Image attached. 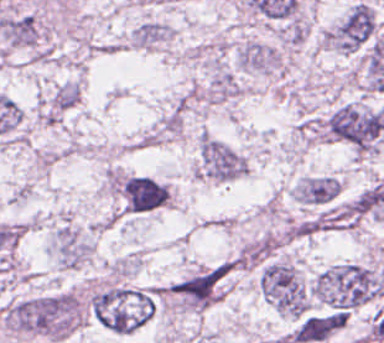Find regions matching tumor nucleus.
I'll return each mask as SVG.
<instances>
[{"label": "tumor nucleus", "instance_id": "2f306a5c", "mask_svg": "<svg viewBox=\"0 0 384 343\" xmlns=\"http://www.w3.org/2000/svg\"><path fill=\"white\" fill-rule=\"evenodd\" d=\"M0 314L12 332L65 337L83 322L84 304L78 292L56 290L14 299Z\"/></svg>", "mask_w": 384, "mask_h": 343}, {"label": "tumor nucleus", "instance_id": "8643909e", "mask_svg": "<svg viewBox=\"0 0 384 343\" xmlns=\"http://www.w3.org/2000/svg\"><path fill=\"white\" fill-rule=\"evenodd\" d=\"M314 300L333 310H350L371 300L380 288L376 267L357 260H338L315 273Z\"/></svg>", "mask_w": 384, "mask_h": 343}, {"label": "tumor nucleus", "instance_id": "5ab6c2c4", "mask_svg": "<svg viewBox=\"0 0 384 343\" xmlns=\"http://www.w3.org/2000/svg\"><path fill=\"white\" fill-rule=\"evenodd\" d=\"M158 294L154 286L112 284L93 289L86 303L98 323L116 333H125L149 318Z\"/></svg>", "mask_w": 384, "mask_h": 343}, {"label": "tumor nucleus", "instance_id": "2cbd58db", "mask_svg": "<svg viewBox=\"0 0 384 343\" xmlns=\"http://www.w3.org/2000/svg\"><path fill=\"white\" fill-rule=\"evenodd\" d=\"M325 133L356 153L367 154L376 149L384 131L372 106L361 101L344 100L329 112Z\"/></svg>", "mask_w": 384, "mask_h": 343}, {"label": "tumor nucleus", "instance_id": "3d1891a8", "mask_svg": "<svg viewBox=\"0 0 384 343\" xmlns=\"http://www.w3.org/2000/svg\"><path fill=\"white\" fill-rule=\"evenodd\" d=\"M258 287L272 308L283 315H303L309 305L308 289L287 259L271 256L263 261Z\"/></svg>", "mask_w": 384, "mask_h": 343}, {"label": "tumor nucleus", "instance_id": "2083b535", "mask_svg": "<svg viewBox=\"0 0 384 343\" xmlns=\"http://www.w3.org/2000/svg\"><path fill=\"white\" fill-rule=\"evenodd\" d=\"M374 29L373 8L367 2L355 0L324 28L320 45L346 54L364 46Z\"/></svg>", "mask_w": 384, "mask_h": 343}, {"label": "tumor nucleus", "instance_id": "8087334f", "mask_svg": "<svg viewBox=\"0 0 384 343\" xmlns=\"http://www.w3.org/2000/svg\"><path fill=\"white\" fill-rule=\"evenodd\" d=\"M195 171L199 176L234 179L246 171V156L215 136L200 134Z\"/></svg>", "mask_w": 384, "mask_h": 343}]
</instances>
